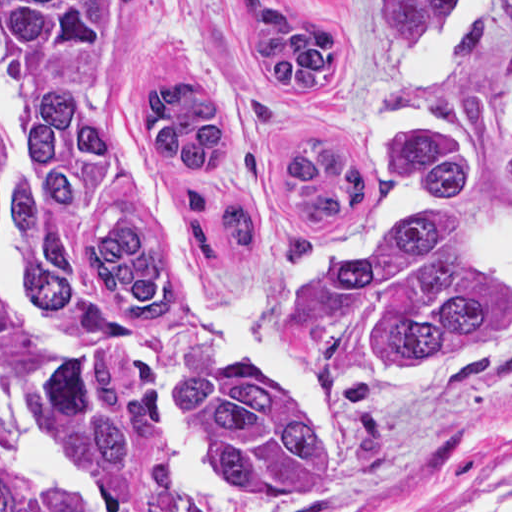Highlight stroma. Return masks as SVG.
Here are the masks:
<instances>
[{"instance_id":"1","label":"stroma","mask_w":512,"mask_h":512,"mask_svg":"<svg viewBox=\"0 0 512 512\" xmlns=\"http://www.w3.org/2000/svg\"><path fill=\"white\" fill-rule=\"evenodd\" d=\"M214 0H108L124 85L163 73ZM367 50L364 70L310 102H284L249 63L238 81V125L206 165H183L188 194L230 183L250 199V251L183 259L190 297L261 355L282 311L326 259L363 246L394 166L386 46L367 0H317ZM512 82V7L481 61V85ZM17 106L0 62V120ZM363 437L341 482L285 512H449L461 463L512 439V358L462 389H388L362 407Z\"/></svg>"}]
</instances>
